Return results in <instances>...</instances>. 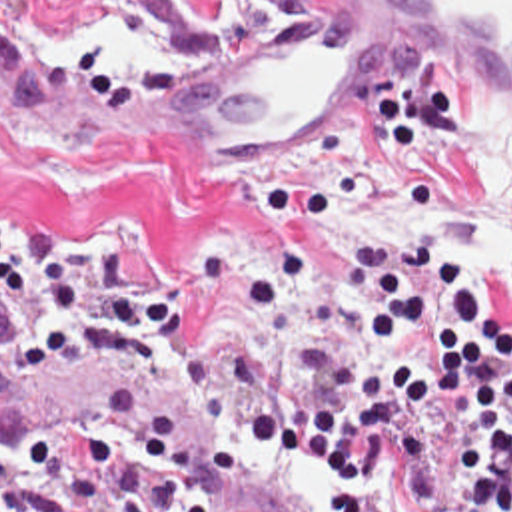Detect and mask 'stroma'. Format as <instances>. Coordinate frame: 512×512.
<instances>
[{"label": "stroma", "mask_w": 512, "mask_h": 512, "mask_svg": "<svg viewBox=\"0 0 512 512\" xmlns=\"http://www.w3.org/2000/svg\"><path fill=\"white\" fill-rule=\"evenodd\" d=\"M302 5L0 0V51L30 63L18 47L30 23L110 21L152 35L170 59L270 31ZM483 105L459 75L410 65L396 103L332 125L312 153L272 163L136 125L0 123V219L30 235L106 243L122 263L162 275L180 299V341L158 369L46 375L88 380L184 420L204 464L244 490L246 512H416L402 448H386L372 480L328 482L246 434L242 416L282 394H332V384L300 367L314 335H350L370 347L382 305L364 289L374 303L366 313L340 311L322 217L358 193L449 203L469 167L461 123ZM423 243L433 257L453 259ZM471 281L491 319L512 323V267L471 269ZM34 313V305L0 301V377L20 369ZM14 446L22 442L0 410V452ZM112 490L120 512H160Z\"/></svg>", "instance_id": "35a3bbf8"}]
</instances>
